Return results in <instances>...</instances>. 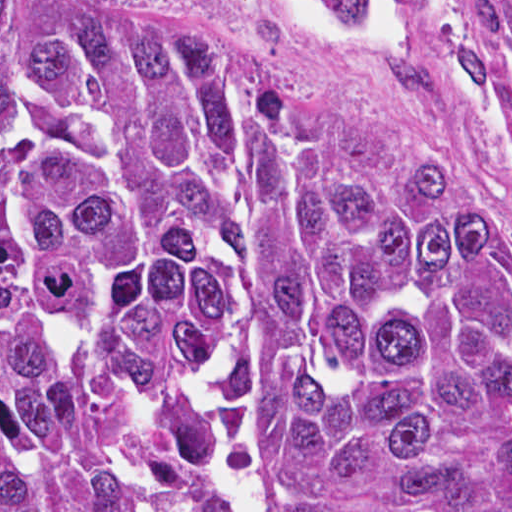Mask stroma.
Here are the masks:
<instances>
[{"mask_svg": "<svg viewBox=\"0 0 512 512\" xmlns=\"http://www.w3.org/2000/svg\"><path fill=\"white\" fill-rule=\"evenodd\" d=\"M222 43L334 107L512 242V72L331 0H41Z\"/></svg>", "mask_w": 512, "mask_h": 512, "instance_id": "35a3bbf8", "label": "stroma"}]
</instances>
